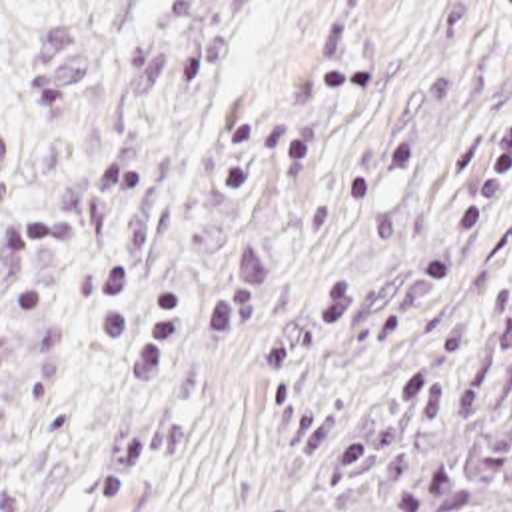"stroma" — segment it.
<instances>
[{
  "mask_svg": "<svg viewBox=\"0 0 512 512\" xmlns=\"http://www.w3.org/2000/svg\"><path fill=\"white\" fill-rule=\"evenodd\" d=\"M511 198L512 0H0V512H292Z\"/></svg>",
  "mask_w": 512,
  "mask_h": 512,
  "instance_id": "stroma-1",
  "label": "stroma"
}]
</instances>
